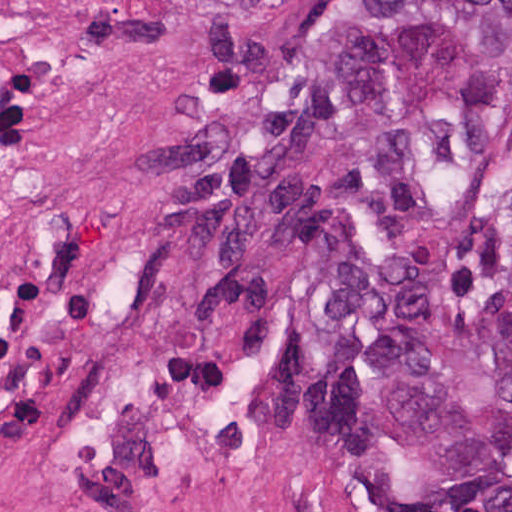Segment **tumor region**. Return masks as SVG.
I'll use <instances>...</instances> for the list:
<instances>
[{"mask_svg": "<svg viewBox=\"0 0 512 512\" xmlns=\"http://www.w3.org/2000/svg\"><path fill=\"white\" fill-rule=\"evenodd\" d=\"M511 145L512 0H339L198 92L158 193L211 347L277 340L235 266L273 242L316 429L405 451L463 512H512Z\"/></svg>", "mask_w": 512, "mask_h": 512, "instance_id": "e687c5a6", "label": "tumor region"}]
</instances>
